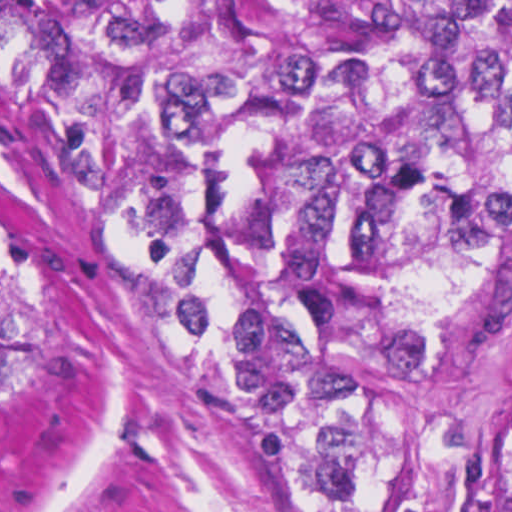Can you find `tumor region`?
I'll use <instances>...</instances> for the list:
<instances>
[{
	"label": "tumor region",
	"mask_w": 512,
	"mask_h": 512,
	"mask_svg": "<svg viewBox=\"0 0 512 512\" xmlns=\"http://www.w3.org/2000/svg\"><path fill=\"white\" fill-rule=\"evenodd\" d=\"M50 1L134 108L219 293L345 450L352 503L384 392L512 316V0ZM0 124L204 391L1 73ZM25 368L0 250V394Z\"/></svg>",
	"instance_id": "tumor-region-1"
}]
</instances>
